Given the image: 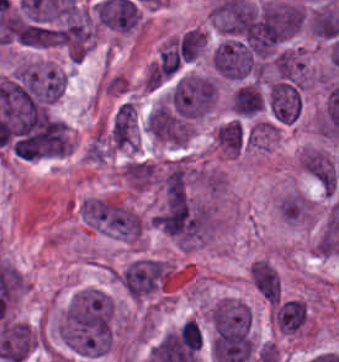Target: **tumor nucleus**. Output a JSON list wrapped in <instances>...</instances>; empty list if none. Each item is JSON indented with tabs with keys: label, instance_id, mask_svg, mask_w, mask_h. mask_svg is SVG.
<instances>
[{
	"label": "tumor nucleus",
	"instance_id": "obj_5",
	"mask_svg": "<svg viewBox=\"0 0 339 362\" xmlns=\"http://www.w3.org/2000/svg\"><path fill=\"white\" fill-rule=\"evenodd\" d=\"M267 101L273 122L292 124L301 112V90L287 81L275 80L268 88Z\"/></svg>",
	"mask_w": 339,
	"mask_h": 362
},
{
	"label": "tumor nucleus",
	"instance_id": "obj_6",
	"mask_svg": "<svg viewBox=\"0 0 339 362\" xmlns=\"http://www.w3.org/2000/svg\"><path fill=\"white\" fill-rule=\"evenodd\" d=\"M300 164L320 185L335 190L339 170L328 157L314 149H307L300 157Z\"/></svg>",
	"mask_w": 339,
	"mask_h": 362
},
{
	"label": "tumor nucleus",
	"instance_id": "obj_10",
	"mask_svg": "<svg viewBox=\"0 0 339 362\" xmlns=\"http://www.w3.org/2000/svg\"><path fill=\"white\" fill-rule=\"evenodd\" d=\"M272 60L279 80L301 85L303 60L297 54L283 51L277 53Z\"/></svg>",
	"mask_w": 339,
	"mask_h": 362
},
{
	"label": "tumor nucleus",
	"instance_id": "obj_9",
	"mask_svg": "<svg viewBox=\"0 0 339 362\" xmlns=\"http://www.w3.org/2000/svg\"><path fill=\"white\" fill-rule=\"evenodd\" d=\"M251 284L266 298L273 302L279 299V281L277 270L267 262L255 260L250 270Z\"/></svg>",
	"mask_w": 339,
	"mask_h": 362
},
{
	"label": "tumor nucleus",
	"instance_id": "obj_7",
	"mask_svg": "<svg viewBox=\"0 0 339 362\" xmlns=\"http://www.w3.org/2000/svg\"><path fill=\"white\" fill-rule=\"evenodd\" d=\"M135 129V116L130 102H123L116 110L108 135L113 147H126L131 143Z\"/></svg>",
	"mask_w": 339,
	"mask_h": 362
},
{
	"label": "tumor nucleus",
	"instance_id": "obj_12",
	"mask_svg": "<svg viewBox=\"0 0 339 362\" xmlns=\"http://www.w3.org/2000/svg\"><path fill=\"white\" fill-rule=\"evenodd\" d=\"M307 211L306 200L297 193H289L282 197L278 206V213L286 221H298L306 215Z\"/></svg>",
	"mask_w": 339,
	"mask_h": 362
},
{
	"label": "tumor nucleus",
	"instance_id": "obj_1",
	"mask_svg": "<svg viewBox=\"0 0 339 362\" xmlns=\"http://www.w3.org/2000/svg\"><path fill=\"white\" fill-rule=\"evenodd\" d=\"M114 301L108 292L76 291L61 326L65 346L82 355H102L113 341Z\"/></svg>",
	"mask_w": 339,
	"mask_h": 362
},
{
	"label": "tumor nucleus",
	"instance_id": "obj_8",
	"mask_svg": "<svg viewBox=\"0 0 339 362\" xmlns=\"http://www.w3.org/2000/svg\"><path fill=\"white\" fill-rule=\"evenodd\" d=\"M273 314L279 332L290 334L303 326L308 311L300 301L289 299L276 304Z\"/></svg>",
	"mask_w": 339,
	"mask_h": 362
},
{
	"label": "tumor nucleus",
	"instance_id": "obj_3",
	"mask_svg": "<svg viewBox=\"0 0 339 362\" xmlns=\"http://www.w3.org/2000/svg\"><path fill=\"white\" fill-rule=\"evenodd\" d=\"M147 128L152 137L171 143L188 139V121L168 102H161L150 112Z\"/></svg>",
	"mask_w": 339,
	"mask_h": 362
},
{
	"label": "tumor nucleus",
	"instance_id": "obj_2",
	"mask_svg": "<svg viewBox=\"0 0 339 362\" xmlns=\"http://www.w3.org/2000/svg\"><path fill=\"white\" fill-rule=\"evenodd\" d=\"M80 215L89 225L115 237L136 238L137 216L121 206L103 200H83Z\"/></svg>",
	"mask_w": 339,
	"mask_h": 362
},
{
	"label": "tumor nucleus",
	"instance_id": "obj_11",
	"mask_svg": "<svg viewBox=\"0 0 339 362\" xmlns=\"http://www.w3.org/2000/svg\"><path fill=\"white\" fill-rule=\"evenodd\" d=\"M215 138L220 147L231 154H239L245 141V132L240 120L235 118L221 126Z\"/></svg>",
	"mask_w": 339,
	"mask_h": 362
},
{
	"label": "tumor nucleus",
	"instance_id": "obj_13",
	"mask_svg": "<svg viewBox=\"0 0 339 362\" xmlns=\"http://www.w3.org/2000/svg\"><path fill=\"white\" fill-rule=\"evenodd\" d=\"M263 100V93L256 84H242L239 116L255 114Z\"/></svg>",
	"mask_w": 339,
	"mask_h": 362
},
{
	"label": "tumor nucleus",
	"instance_id": "obj_4",
	"mask_svg": "<svg viewBox=\"0 0 339 362\" xmlns=\"http://www.w3.org/2000/svg\"><path fill=\"white\" fill-rule=\"evenodd\" d=\"M163 270L161 260L138 258L126 265L120 284L133 297H141L158 286Z\"/></svg>",
	"mask_w": 339,
	"mask_h": 362
}]
</instances>
